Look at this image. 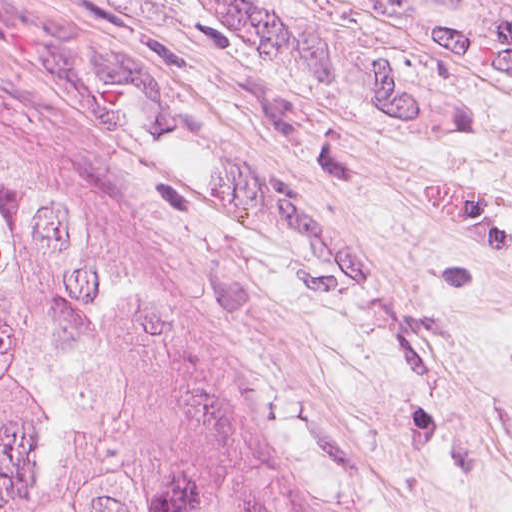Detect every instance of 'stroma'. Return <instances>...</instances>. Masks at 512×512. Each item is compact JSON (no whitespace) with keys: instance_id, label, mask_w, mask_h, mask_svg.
Returning a JSON list of instances; mask_svg holds the SVG:
<instances>
[{"instance_id":"35a3bbf8","label":"stroma","mask_w":512,"mask_h":512,"mask_svg":"<svg viewBox=\"0 0 512 512\" xmlns=\"http://www.w3.org/2000/svg\"><path fill=\"white\" fill-rule=\"evenodd\" d=\"M0 134L263 512H512V0H0Z\"/></svg>"}]
</instances>
